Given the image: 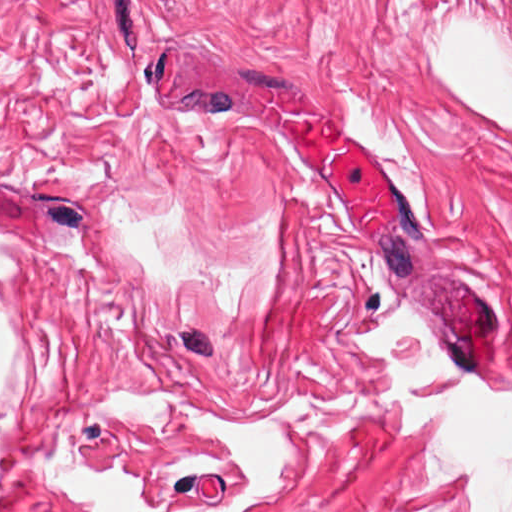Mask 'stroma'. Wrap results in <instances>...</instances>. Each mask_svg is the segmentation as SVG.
I'll return each mask as SVG.
<instances>
[{
	"mask_svg": "<svg viewBox=\"0 0 512 512\" xmlns=\"http://www.w3.org/2000/svg\"><path fill=\"white\" fill-rule=\"evenodd\" d=\"M512 41V0H0V273L25 360L0 389V512H86L77 453L160 500L218 506L238 462L210 419L156 436L94 403L193 386L234 420L290 396L292 487L252 512H466L380 402L354 338L404 303L494 382L510 334L512 126L431 79L455 17ZM270 110H319L392 177L380 227L306 173Z\"/></svg>",
	"mask_w": 512,
	"mask_h": 512,
	"instance_id": "obj_1",
	"label": "stroma"
}]
</instances>
